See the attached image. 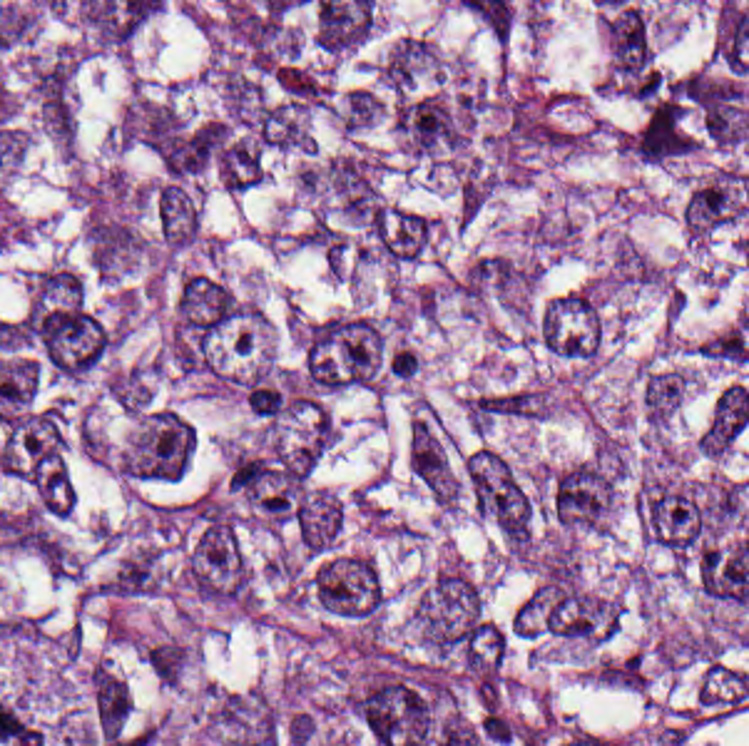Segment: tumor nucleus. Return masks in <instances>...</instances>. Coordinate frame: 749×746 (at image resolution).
I'll use <instances>...</instances> for the list:
<instances>
[{
	"mask_svg": "<svg viewBox=\"0 0 749 746\" xmlns=\"http://www.w3.org/2000/svg\"><path fill=\"white\" fill-rule=\"evenodd\" d=\"M464 482L472 510L522 552L532 540L535 502L505 459L474 449L464 464Z\"/></svg>",
	"mask_w": 749,
	"mask_h": 746,
	"instance_id": "obj_1",
	"label": "tumor nucleus"
},
{
	"mask_svg": "<svg viewBox=\"0 0 749 746\" xmlns=\"http://www.w3.org/2000/svg\"><path fill=\"white\" fill-rule=\"evenodd\" d=\"M305 593L310 603L335 617L373 620L383 602V583L371 556L330 549L312 561Z\"/></svg>",
	"mask_w": 749,
	"mask_h": 746,
	"instance_id": "obj_2",
	"label": "tumor nucleus"
},
{
	"mask_svg": "<svg viewBox=\"0 0 749 746\" xmlns=\"http://www.w3.org/2000/svg\"><path fill=\"white\" fill-rule=\"evenodd\" d=\"M189 425L166 407L143 415L121 449L118 473L131 480H174L187 464Z\"/></svg>",
	"mask_w": 749,
	"mask_h": 746,
	"instance_id": "obj_3",
	"label": "tumor nucleus"
},
{
	"mask_svg": "<svg viewBox=\"0 0 749 746\" xmlns=\"http://www.w3.org/2000/svg\"><path fill=\"white\" fill-rule=\"evenodd\" d=\"M615 482V467L591 457L564 467L546 487L550 518L561 528H600Z\"/></svg>",
	"mask_w": 749,
	"mask_h": 746,
	"instance_id": "obj_4",
	"label": "tumor nucleus"
},
{
	"mask_svg": "<svg viewBox=\"0 0 749 746\" xmlns=\"http://www.w3.org/2000/svg\"><path fill=\"white\" fill-rule=\"evenodd\" d=\"M241 316L236 290L221 276L188 270L170 297V326L183 336H214Z\"/></svg>",
	"mask_w": 749,
	"mask_h": 746,
	"instance_id": "obj_5",
	"label": "tumor nucleus"
},
{
	"mask_svg": "<svg viewBox=\"0 0 749 746\" xmlns=\"http://www.w3.org/2000/svg\"><path fill=\"white\" fill-rule=\"evenodd\" d=\"M600 314L587 290H561L538 309L534 336L549 353L582 361L596 344Z\"/></svg>",
	"mask_w": 749,
	"mask_h": 746,
	"instance_id": "obj_6",
	"label": "tumor nucleus"
},
{
	"mask_svg": "<svg viewBox=\"0 0 749 746\" xmlns=\"http://www.w3.org/2000/svg\"><path fill=\"white\" fill-rule=\"evenodd\" d=\"M404 463L429 498L455 503L458 478L433 420L420 410L404 431Z\"/></svg>",
	"mask_w": 749,
	"mask_h": 746,
	"instance_id": "obj_7",
	"label": "tumor nucleus"
},
{
	"mask_svg": "<svg viewBox=\"0 0 749 746\" xmlns=\"http://www.w3.org/2000/svg\"><path fill=\"white\" fill-rule=\"evenodd\" d=\"M527 263L500 253H487L455 280L457 291L474 299L517 301L528 287Z\"/></svg>",
	"mask_w": 749,
	"mask_h": 746,
	"instance_id": "obj_8",
	"label": "tumor nucleus"
},
{
	"mask_svg": "<svg viewBox=\"0 0 749 746\" xmlns=\"http://www.w3.org/2000/svg\"><path fill=\"white\" fill-rule=\"evenodd\" d=\"M151 200L154 228L164 243L191 246L199 234L194 188L186 183H155Z\"/></svg>",
	"mask_w": 749,
	"mask_h": 746,
	"instance_id": "obj_9",
	"label": "tumor nucleus"
},
{
	"mask_svg": "<svg viewBox=\"0 0 749 746\" xmlns=\"http://www.w3.org/2000/svg\"><path fill=\"white\" fill-rule=\"evenodd\" d=\"M88 708L96 737L123 726L129 714V687L107 665L95 660L86 671Z\"/></svg>",
	"mask_w": 749,
	"mask_h": 746,
	"instance_id": "obj_10",
	"label": "tumor nucleus"
},
{
	"mask_svg": "<svg viewBox=\"0 0 749 746\" xmlns=\"http://www.w3.org/2000/svg\"><path fill=\"white\" fill-rule=\"evenodd\" d=\"M86 242L96 271L109 274L132 259L139 230L122 215L101 213L88 220Z\"/></svg>",
	"mask_w": 749,
	"mask_h": 746,
	"instance_id": "obj_11",
	"label": "tumor nucleus"
},
{
	"mask_svg": "<svg viewBox=\"0 0 749 746\" xmlns=\"http://www.w3.org/2000/svg\"><path fill=\"white\" fill-rule=\"evenodd\" d=\"M683 394L682 375L674 367H648L642 371L638 400L643 421L664 423Z\"/></svg>",
	"mask_w": 749,
	"mask_h": 746,
	"instance_id": "obj_12",
	"label": "tumor nucleus"
},
{
	"mask_svg": "<svg viewBox=\"0 0 749 746\" xmlns=\"http://www.w3.org/2000/svg\"><path fill=\"white\" fill-rule=\"evenodd\" d=\"M432 48L415 34H402L388 48L380 79L393 94L410 87L420 76Z\"/></svg>",
	"mask_w": 749,
	"mask_h": 746,
	"instance_id": "obj_13",
	"label": "tumor nucleus"
},
{
	"mask_svg": "<svg viewBox=\"0 0 749 746\" xmlns=\"http://www.w3.org/2000/svg\"><path fill=\"white\" fill-rule=\"evenodd\" d=\"M380 110L378 93L356 86L335 101L339 126L357 132L376 122Z\"/></svg>",
	"mask_w": 749,
	"mask_h": 746,
	"instance_id": "obj_14",
	"label": "tumor nucleus"
}]
</instances>
